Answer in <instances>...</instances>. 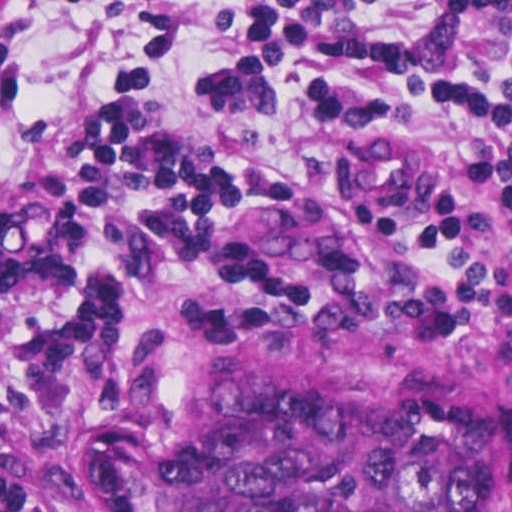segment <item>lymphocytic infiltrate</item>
<instances>
[{
  "label": "lymphocytic infiltrate",
  "mask_w": 512,
  "mask_h": 512,
  "mask_svg": "<svg viewBox=\"0 0 512 512\" xmlns=\"http://www.w3.org/2000/svg\"><path fill=\"white\" fill-rule=\"evenodd\" d=\"M203 70L219 109L290 108L307 171L252 173L166 121L149 76H120L55 177L35 159L0 208V512H43L47 441L77 357L115 307L267 304L231 286L228 211L258 190L347 198L386 231L382 299L512 301V0H227ZM136 58L182 48L188 0H116ZM322 194L319 191H316Z\"/></svg>",
  "instance_id": "lymphocytic-infiltrate-1"
}]
</instances>
